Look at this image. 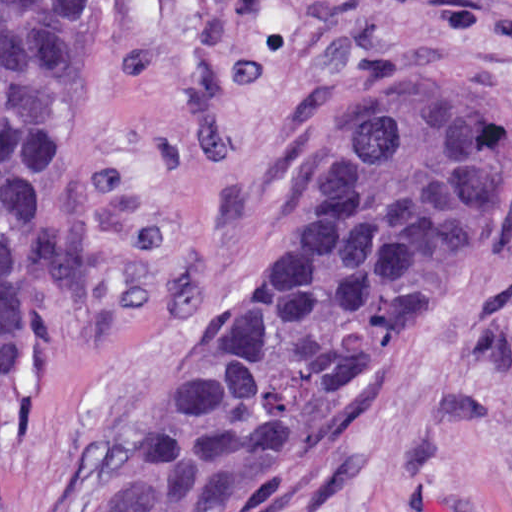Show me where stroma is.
Instances as JSON below:
<instances>
[{"label":"stroma","instance_id":"stroma-1","mask_svg":"<svg viewBox=\"0 0 512 512\" xmlns=\"http://www.w3.org/2000/svg\"><path fill=\"white\" fill-rule=\"evenodd\" d=\"M1 1H83L64 241L1 430ZM417 61L512 97V0H0V512H80L277 266L339 100ZM284 512H512V219Z\"/></svg>","mask_w":512,"mask_h":512}]
</instances>
